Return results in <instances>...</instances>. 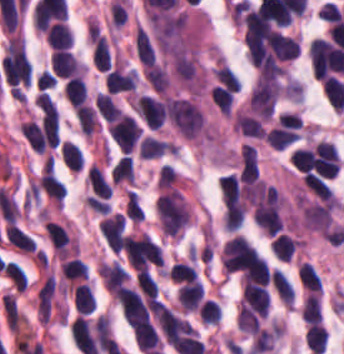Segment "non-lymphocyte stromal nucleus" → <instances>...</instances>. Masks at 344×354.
<instances>
[{"label": "non-lymphocyte stromal nucleus", "mask_w": 344, "mask_h": 354, "mask_svg": "<svg viewBox=\"0 0 344 354\" xmlns=\"http://www.w3.org/2000/svg\"><path fill=\"white\" fill-rule=\"evenodd\" d=\"M138 57L143 63L151 64L156 61V49L144 27L137 24L133 40Z\"/></svg>", "instance_id": "2"}, {"label": "non-lymphocyte stromal nucleus", "mask_w": 344, "mask_h": 354, "mask_svg": "<svg viewBox=\"0 0 344 354\" xmlns=\"http://www.w3.org/2000/svg\"><path fill=\"white\" fill-rule=\"evenodd\" d=\"M4 233L13 248L26 252L28 254L34 251L35 241L33 237H31L15 225L9 223L4 228Z\"/></svg>", "instance_id": "3"}, {"label": "non-lymphocyte stromal nucleus", "mask_w": 344, "mask_h": 354, "mask_svg": "<svg viewBox=\"0 0 344 354\" xmlns=\"http://www.w3.org/2000/svg\"><path fill=\"white\" fill-rule=\"evenodd\" d=\"M283 70L260 72L248 97L254 110H272L282 92Z\"/></svg>", "instance_id": "1"}]
</instances>
